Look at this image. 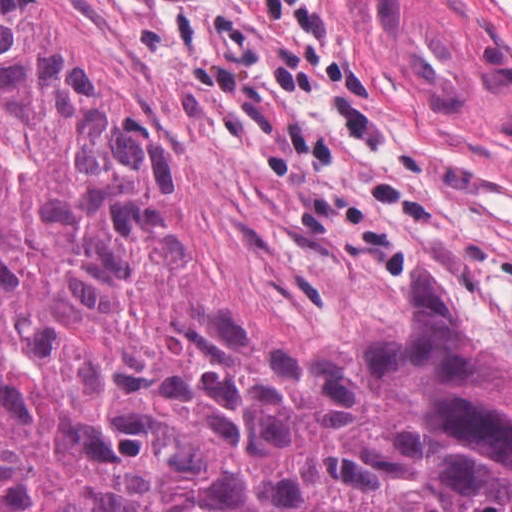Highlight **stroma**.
I'll return each mask as SVG.
<instances>
[{"instance_id":"1","label":"stroma","mask_w":512,"mask_h":512,"mask_svg":"<svg viewBox=\"0 0 512 512\" xmlns=\"http://www.w3.org/2000/svg\"><path fill=\"white\" fill-rule=\"evenodd\" d=\"M47 1L109 105L175 163L184 268L159 293L165 309L237 315L271 351H293L407 323L427 257L512 362V0H334L394 145L355 140L321 113L298 118L379 191L419 187L437 205L405 220L412 257L398 262L319 245L273 177L160 98L94 0Z\"/></svg>"}]
</instances>
